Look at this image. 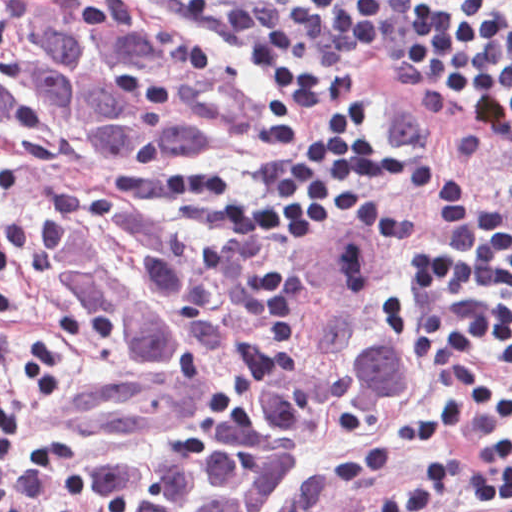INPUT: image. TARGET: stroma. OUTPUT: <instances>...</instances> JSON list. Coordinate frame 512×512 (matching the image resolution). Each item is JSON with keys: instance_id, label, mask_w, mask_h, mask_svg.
Instances as JSON below:
<instances>
[{"instance_id": "stroma-1", "label": "stroma", "mask_w": 512, "mask_h": 512, "mask_svg": "<svg viewBox=\"0 0 512 512\" xmlns=\"http://www.w3.org/2000/svg\"><path fill=\"white\" fill-rule=\"evenodd\" d=\"M100 4L155 39L190 54L245 88L256 102V128L235 150H43L0 142V351L46 383L58 396H74L121 373L112 356L89 339L53 303L35 268L38 230L67 199L109 196L152 216L170 234L188 241L224 245H306L275 243L259 236H229L213 221L168 196L171 174L224 181L237 194L257 201L270 167L264 131L279 102L290 105L306 126L329 105H301L284 98L260 75L254 57L235 47L224 30L194 23L177 10L147 0H89ZM512 15V0H474ZM392 8L395 3H391ZM355 92L377 94L387 109V143L416 163L458 169L492 186L512 208V147L453 109L443 80L410 75L380 59L376 45L357 75ZM411 205L406 193L376 189L361 198L350 227L379 232L393 272L415 318L409 290L401 282L397 246L376 218L380 208L400 212ZM340 230V231H341ZM324 240V239H323ZM322 241V240H319ZM420 328V327H419ZM463 404L437 384L425 354V373L400 411L365 438L347 440L319 457L274 512H368L434 462L453 472L429 495L419 512H488L464 496L480 460L463 436H449L425 451L389 458L384 468L351 495L327 494V474L352 451L424 406Z\"/></svg>"}]
</instances>
